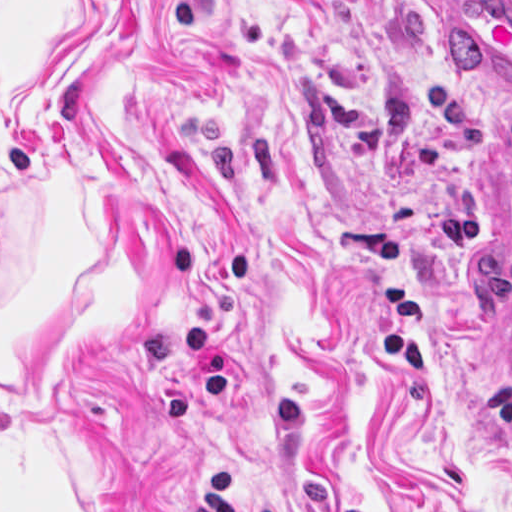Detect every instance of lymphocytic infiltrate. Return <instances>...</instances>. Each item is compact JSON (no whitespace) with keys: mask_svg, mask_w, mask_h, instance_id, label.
I'll return each instance as SVG.
<instances>
[{"mask_svg":"<svg viewBox=\"0 0 512 512\" xmlns=\"http://www.w3.org/2000/svg\"><path fill=\"white\" fill-rule=\"evenodd\" d=\"M191 512H233V478L222 465L194 488ZM496 512H512V505Z\"/></svg>","mask_w":512,"mask_h":512,"instance_id":"f902f5d3","label":"lymphocytic infiltrate"}]
</instances>
